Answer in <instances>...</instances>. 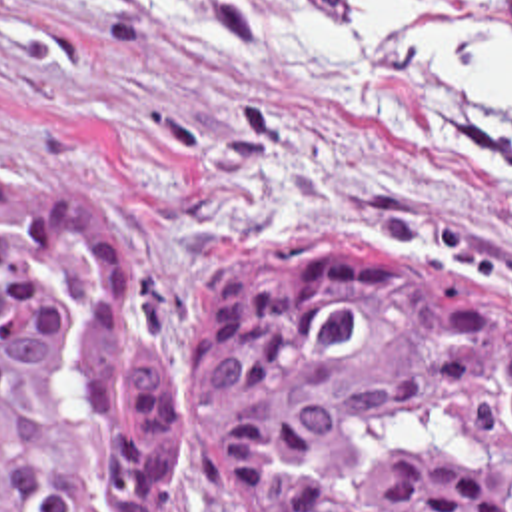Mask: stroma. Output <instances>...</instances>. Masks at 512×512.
Here are the masks:
<instances>
[{
	"label": "stroma",
	"mask_w": 512,
	"mask_h": 512,
	"mask_svg": "<svg viewBox=\"0 0 512 512\" xmlns=\"http://www.w3.org/2000/svg\"><path fill=\"white\" fill-rule=\"evenodd\" d=\"M0 0V179L86 193L128 301L174 365L224 273L308 241L352 239L512 305V119L470 105L432 45L472 33L512 55V1L424 0L382 51L366 111L294 91L256 31L330 0ZM180 512H242L200 488Z\"/></svg>",
	"instance_id": "stroma-1"
}]
</instances>
